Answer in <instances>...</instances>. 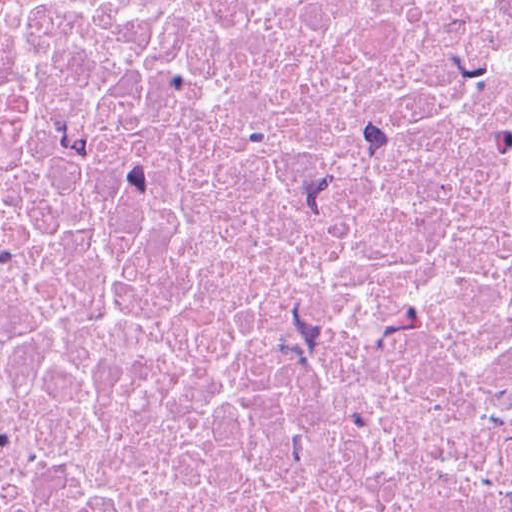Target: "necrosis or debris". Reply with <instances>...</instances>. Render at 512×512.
I'll return each mask as SVG.
<instances>
[{"label":"necrosis or debris","instance_id":"1","mask_svg":"<svg viewBox=\"0 0 512 512\" xmlns=\"http://www.w3.org/2000/svg\"><path fill=\"white\" fill-rule=\"evenodd\" d=\"M0 512H512V0H0Z\"/></svg>","mask_w":512,"mask_h":512}]
</instances>
